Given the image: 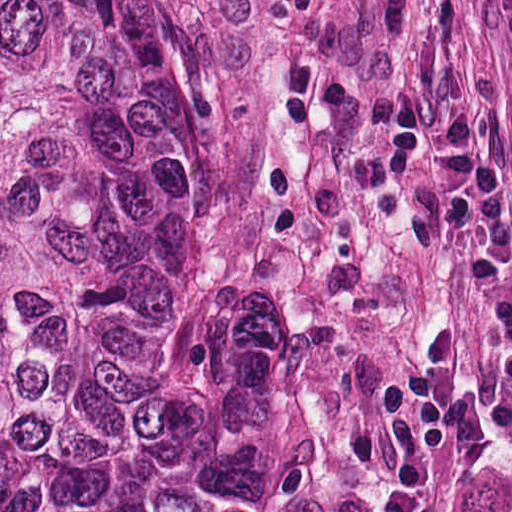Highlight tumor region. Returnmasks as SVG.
Returning a JSON list of instances; mask_svg holds the SVG:
<instances>
[{
  "label": "tumor region",
  "mask_w": 512,
  "mask_h": 512,
  "mask_svg": "<svg viewBox=\"0 0 512 512\" xmlns=\"http://www.w3.org/2000/svg\"><path fill=\"white\" fill-rule=\"evenodd\" d=\"M0 512H426L361 365L204 259L189 0H0Z\"/></svg>",
  "instance_id": "1"
}]
</instances>
